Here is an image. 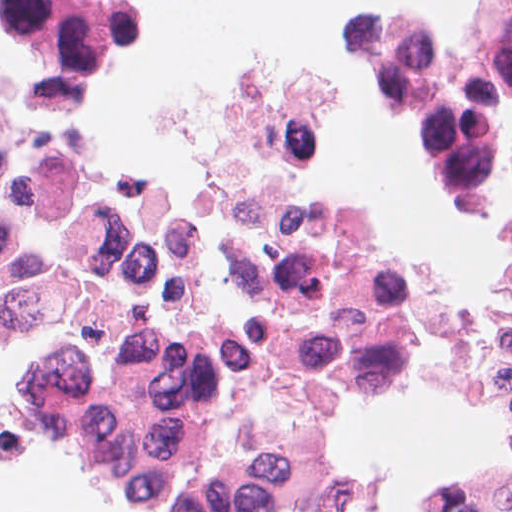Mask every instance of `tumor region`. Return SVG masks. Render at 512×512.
I'll return each instance as SVG.
<instances>
[{
	"label": "tumor region",
	"mask_w": 512,
	"mask_h": 512,
	"mask_svg": "<svg viewBox=\"0 0 512 512\" xmlns=\"http://www.w3.org/2000/svg\"><path fill=\"white\" fill-rule=\"evenodd\" d=\"M12 432L26 449L87 472L101 496L117 511L154 512L124 488L69 385L41 351L34 371L12 399ZM504 512H512V506Z\"/></svg>",
	"instance_id": "tumor-region-1"
}]
</instances>
